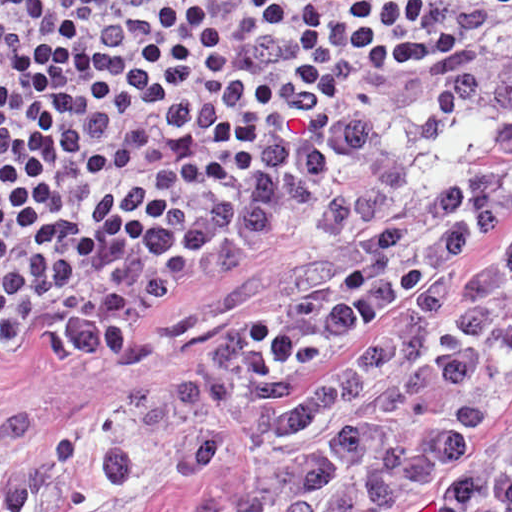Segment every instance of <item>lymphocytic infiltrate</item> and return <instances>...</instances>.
Here are the masks:
<instances>
[{
  "label": "lymphocytic infiltrate",
  "mask_w": 512,
  "mask_h": 512,
  "mask_svg": "<svg viewBox=\"0 0 512 512\" xmlns=\"http://www.w3.org/2000/svg\"><path fill=\"white\" fill-rule=\"evenodd\" d=\"M512 0H1V309L365 67L475 47Z\"/></svg>",
  "instance_id": "1"
}]
</instances>
